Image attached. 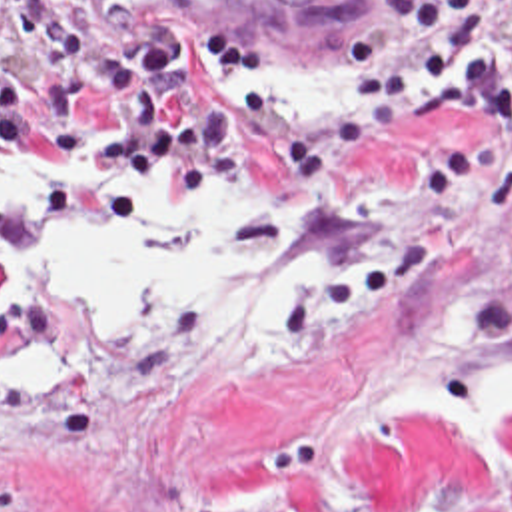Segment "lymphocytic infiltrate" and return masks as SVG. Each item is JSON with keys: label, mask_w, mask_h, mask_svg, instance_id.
I'll return each instance as SVG.
<instances>
[{"label": "lymphocytic infiltrate", "mask_w": 512, "mask_h": 512, "mask_svg": "<svg viewBox=\"0 0 512 512\" xmlns=\"http://www.w3.org/2000/svg\"><path fill=\"white\" fill-rule=\"evenodd\" d=\"M340 41L368 123L424 117L442 97L476 109L490 149L512 143V0H394Z\"/></svg>", "instance_id": "lymphocytic-infiltrate-1"}]
</instances>
